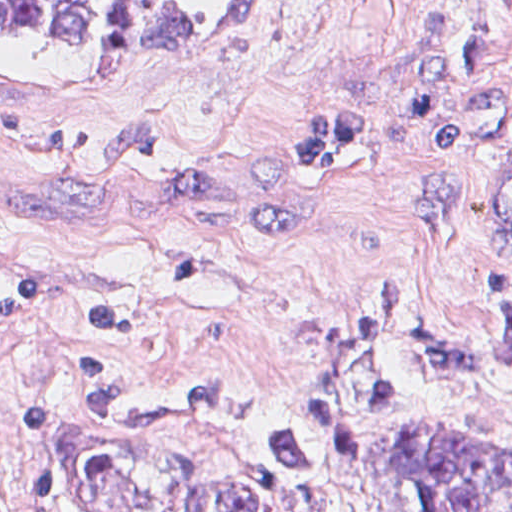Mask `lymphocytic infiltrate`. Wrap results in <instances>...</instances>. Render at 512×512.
<instances>
[{
    "instance_id": "lymphocytic-infiltrate-1",
    "label": "lymphocytic infiltrate",
    "mask_w": 512,
    "mask_h": 512,
    "mask_svg": "<svg viewBox=\"0 0 512 512\" xmlns=\"http://www.w3.org/2000/svg\"><path fill=\"white\" fill-rule=\"evenodd\" d=\"M59 415L53 398L35 392L23 410L21 477L28 512H67L47 464V444Z\"/></svg>"
}]
</instances>
